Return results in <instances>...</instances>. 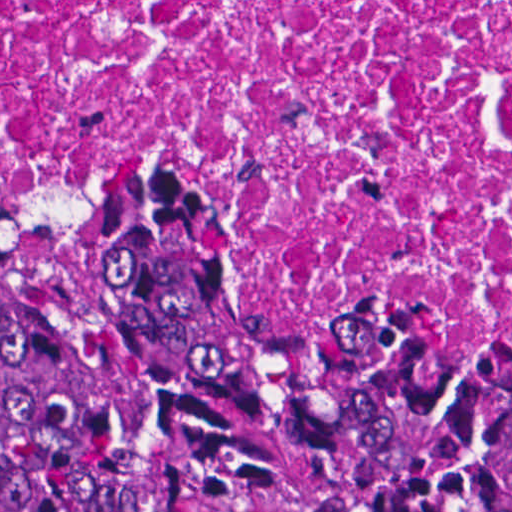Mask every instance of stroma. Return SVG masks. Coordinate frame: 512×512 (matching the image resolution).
<instances>
[{"label": "stroma", "mask_w": 512, "mask_h": 512, "mask_svg": "<svg viewBox=\"0 0 512 512\" xmlns=\"http://www.w3.org/2000/svg\"><path fill=\"white\" fill-rule=\"evenodd\" d=\"M95 204H67L31 220L1 214L0 0V512H50L1 479V264L38 258L83 235ZM208 266L240 297L274 312L312 320H365L446 334L483 351L474 312L402 297H352L318 284L204 214Z\"/></svg>", "instance_id": "35a3bbf8"}]
</instances>
